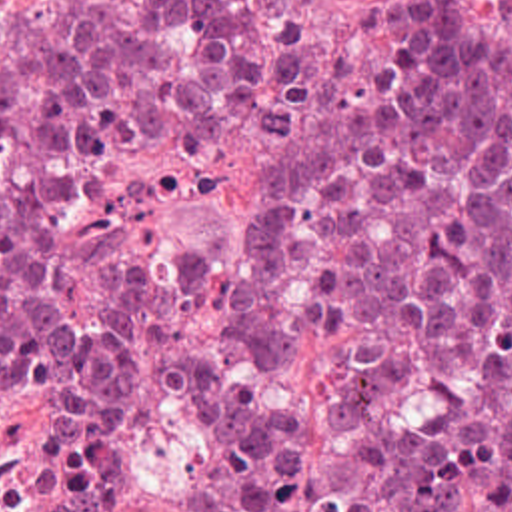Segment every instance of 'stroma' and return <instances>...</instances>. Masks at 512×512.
Wrapping results in <instances>:
<instances>
[{"mask_svg": "<svg viewBox=\"0 0 512 512\" xmlns=\"http://www.w3.org/2000/svg\"><path fill=\"white\" fill-rule=\"evenodd\" d=\"M61 0H5L51 9ZM512 37V0H457ZM317 41L329 55L363 63L385 41L387 0H311ZM271 185V141L251 107L175 151H39L0 135V193H57L63 223L55 271L69 313L107 311L139 251L179 245L211 275L251 269L259 211Z\"/></svg>", "mask_w": 512, "mask_h": 512, "instance_id": "1", "label": "stroma"}]
</instances>
